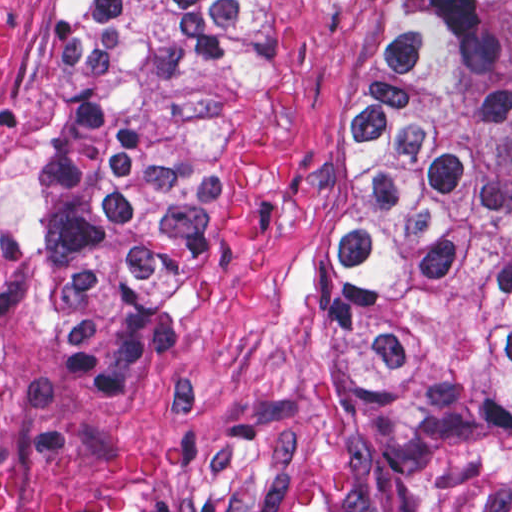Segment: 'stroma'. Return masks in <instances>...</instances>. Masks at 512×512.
Listing matches in <instances>:
<instances>
[{"label":"stroma","mask_w":512,"mask_h":512,"mask_svg":"<svg viewBox=\"0 0 512 512\" xmlns=\"http://www.w3.org/2000/svg\"><path fill=\"white\" fill-rule=\"evenodd\" d=\"M61 1L28 0L0 65V332L40 415L198 462L225 512H512V494L381 457L332 380L343 117L393 0H261L223 96L228 275L126 366L84 357L76 325L6 242V213L74 83Z\"/></svg>","instance_id":"stroma-1"}]
</instances>
